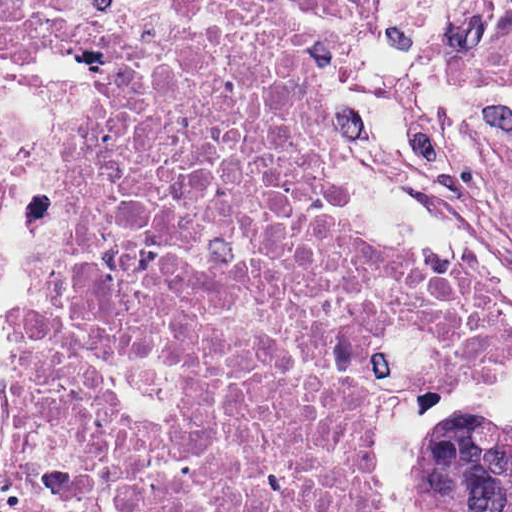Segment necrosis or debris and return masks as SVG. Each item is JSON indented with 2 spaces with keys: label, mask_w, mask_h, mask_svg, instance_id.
<instances>
[{
  "label": "necrosis or debris",
  "mask_w": 512,
  "mask_h": 512,
  "mask_svg": "<svg viewBox=\"0 0 512 512\" xmlns=\"http://www.w3.org/2000/svg\"><path fill=\"white\" fill-rule=\"evenodd\" d=\"M96 85L43 299L5 296L8 512H377L373 396L512 353V308L344 216L334 66L306 13H7Z\"/></svg>",
  "instance_id": "necrosis-or-debris-1"
}]
</instances>
